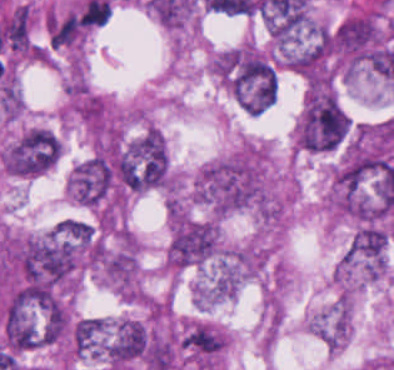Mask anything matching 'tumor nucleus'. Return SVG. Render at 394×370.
Listing matches in <instances>:
<instances>
[{
  "label": "tumor nucleus",
  "mask_w": 394,
  "mask_h": 370,
  "mask_svg": "<svg viewBox=\"0 0 394 370\" xmlns=\"http://www.w3.org/2000/svg\"><path fill=\"white\" fill-rule=\"evenodd\" d=\"M59 155L58 137L44 126H31L3 149L1 161L6 173L34 177L52 167Z\"/></svg>",
  "instance_id": "1"
},
{
  "label": "tumor nucleus",
  "mask_w": 394,
  "mask_h": 370,
  "mask_svg": "<svg viewBox=\"0 0 394 370\" xmlns=\"http://www.w3.org/2000/svg\"><path fill=\"white\" fill-rule=\"evenodd\" d=\"M108 367L118 370L148 367L151 363L149 331L146 326L128 317L110 323Z\"/></svg>",
  "instance_id": "2"
}]
</instances>
